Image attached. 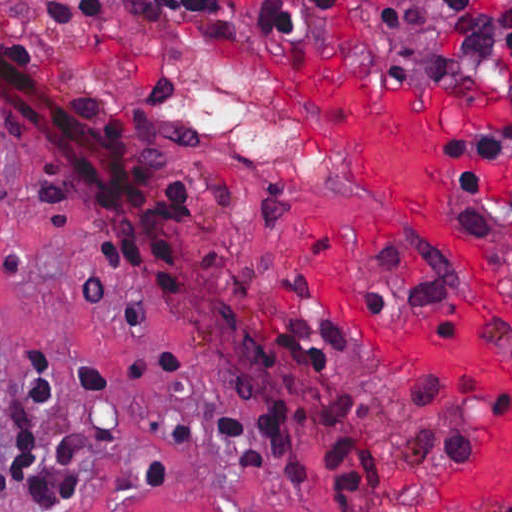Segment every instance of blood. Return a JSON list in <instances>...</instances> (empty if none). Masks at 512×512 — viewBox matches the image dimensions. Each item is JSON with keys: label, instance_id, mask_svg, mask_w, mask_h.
Wrapping results in <instances>:
<instances>
[{"label": "blood", "instance_id": "1", "mask_svg": "<svg viewBox=\"0 0 512 512\" xmlns=\"http://www.w3.org/2000/svg\"><path fill=\"white\" fill-rule=\"evenodd\" d=\"M310 111L348 172L409 211L446 247L472 261L457 322L444 327L393 314L377 284L316 233L378 353L396 363L497 377L504 409L478 434L469 465L444 487L488 512H512V274L447 225L433 179L439 107L423 92L354 83H307Z\"/></svg>", "mask_w": 512, "mask_h": 512}]
</instances>
